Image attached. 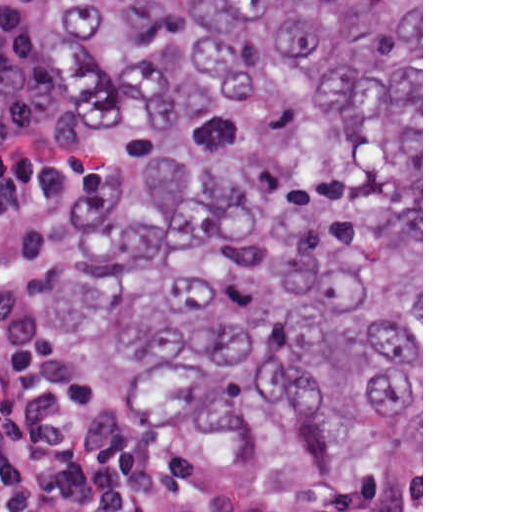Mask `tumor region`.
<instances>
[{
	"label": "tumor region",
	"mask_w": 512,
	"mask_h": 512,
	"mask_svg": "<svg viewBox=\"0 0 512 512\" xmlns=\"http://www.w3.org/2000/svg\"><path fill=\"white\" fill-rule=\"evenodd\" d=\"M96 170L0 317L201 449L403 489L421 449V0H68Z\"/></svg>",
	"instance_id": "obj_1"
}]
</instances>
